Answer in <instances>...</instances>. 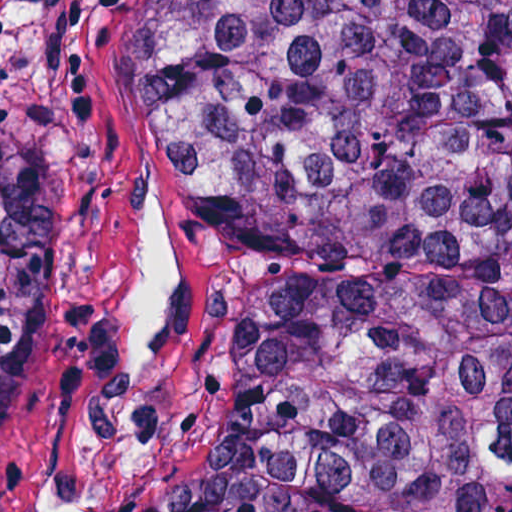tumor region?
I'll return each instance as SVG.
<instances>
[{"mask_svg": "<svg viewBox=\"0 0 512 512\" xmlns=\"http://www.w3.org/2000/svg\"><path fill=\"white\" fill-rule=\"evenodd\" d=\"M122 109L235 220L204 439L131 512H512V0H139ZM37 267L38 0H0V424Z\"/></svg>", "mask_w": 512, "mask_h": 512, "instance_id": "obj_1", "label": "tumor region"}]
</instances>
